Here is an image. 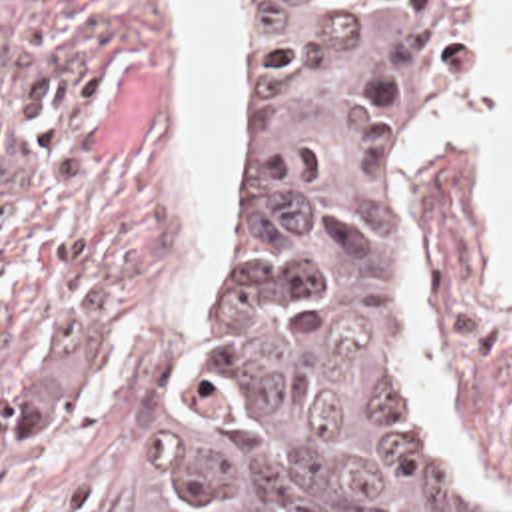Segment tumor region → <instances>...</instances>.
Instances as JSON below:
<instances>
[{
    "label": "tumor region",
    "mask_w": 512,
    "mask_h": 512,
    "mask_svg": "<svg viewBox=\"0 0 512 512\" xmlns=\"http://www.w3.org/2000/svg\"><path fill=\"white\" fill-rule=\"evenodd\" d=\"M459 0H253L263 233L142 512H509L419 358L397 163Z\"/></svg>",
    "instance_id": "tumor-region-1"
}]
</instances>
